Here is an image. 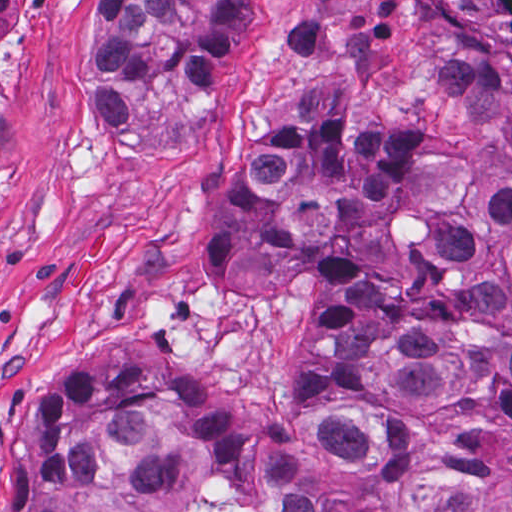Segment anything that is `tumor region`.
<instances>
[{
  "label": "tumor region",
  "mask_w": 512,
  "mask_h": 512,
  "mask_svg": "<svg viewBox=\"0 0 512 512\" xmlns=\"http://www.w3.org/2000/svg\"><path fill=\"white\" fill-rule=\"evenodd\" d=\"M1 0V119L14 31ZM450 84L512 126V0H426ZM251 0H107L96 146L176 77L217 101ZM208 287L308 305L283 413L203 395L135 311L112 310L28 389L1 512H460L484 475L512 512V184L441 128L283 99L213 176Z\"/></svg>",
  "instance_id": "1"
}]
</instances>
